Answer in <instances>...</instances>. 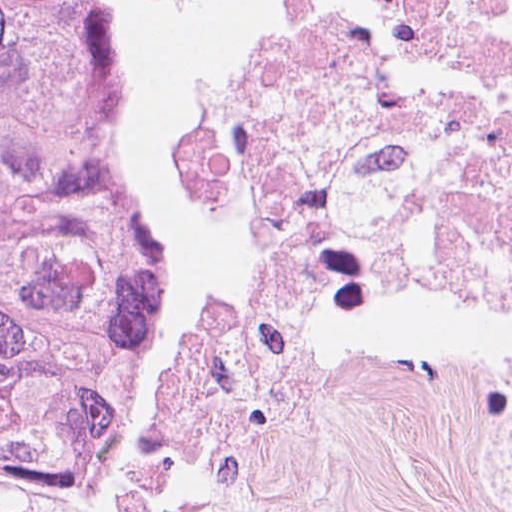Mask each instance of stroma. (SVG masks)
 Instances as JSON below:
<instances>
[{"label":"stroma","instance_id":"35a3bbf8","mask_svg":"<svg viewBox=\"0 0 512 512\" xmlns=\"http://www.w3.org/2000/svg\"><path fill=\"white\" fill-rule=\"evenodd\" d=\"M129 112V154L189 311L183 409L66 461L0 454V512H512L478 383L512 323L437 275H290L237 240L227 103L145 0H77Z\"/></svg>","mask_w":512,"mask_h":512}]
</instances>
